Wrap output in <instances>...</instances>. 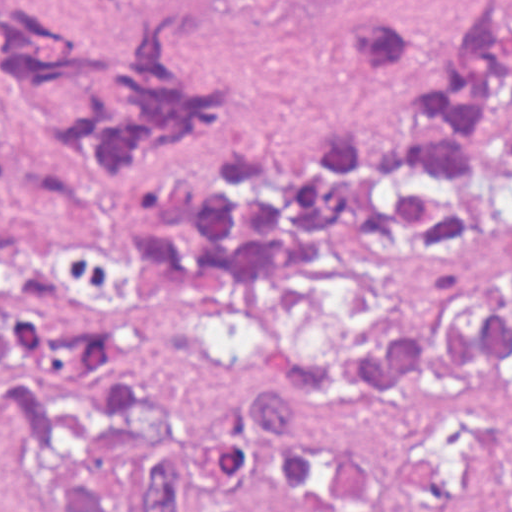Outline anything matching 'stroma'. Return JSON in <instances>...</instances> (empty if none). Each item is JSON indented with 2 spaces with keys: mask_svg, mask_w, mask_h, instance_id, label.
Listing matches in <instances>:
<instances>
[{
  "mask_svg": "<svg viewBox=\"0 0 512 512\" xmlns=\"http://www.w3.org/2000/svg\"><path fill=\"white\" fill-rule=\"evenodd\" d=\"M70 6L72 0H49ZM493 0H182L198 29L243 64L238 98L173 162L207 178L239 148L295 153L344 127L401 131L423 101L363 66L353 30L368 17L404 18L445 35ZM512 1V0H509ZM33 219L118 257L122 299L88 320L102 340L145 344L164 396L161 448L134 480L121 512H136L177 434L254 391L266 339L242 298L166 295L125 245L123 219ZM512 457V388L457 385L328 412L254 462L208 512H443ZM0 512H54L15 471V432L0 429Z\"/></svg>",
  "mask_w": 512,
  "mask_h": 512,
  "instance_id": "35a3bbf8",
  "label": "stroma"
}]
</instances>
